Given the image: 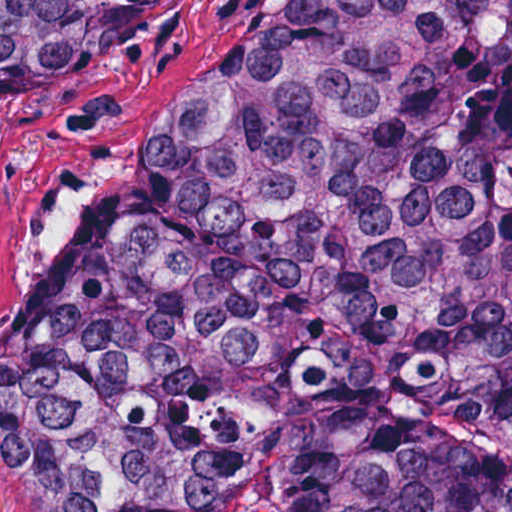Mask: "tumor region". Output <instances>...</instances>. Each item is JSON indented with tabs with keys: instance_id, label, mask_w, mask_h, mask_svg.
<instances>
[{
	"instance_id": "obj_1",
	"label": "tumor region",
	"mask_w": 512,
	"mask_h": 512,
	"mask_svg": "<svg viewBox=\"0 0 512 512\" xmlns=\"http://www.w3.org/2000/svg\"><path fill=\"white\" fill-rule=\"evenodd\" d=\"M174 0H0L38 93ZM42 512H512V0H271L125 121L0 323Z\"/></svg>"
}]
</instances>
